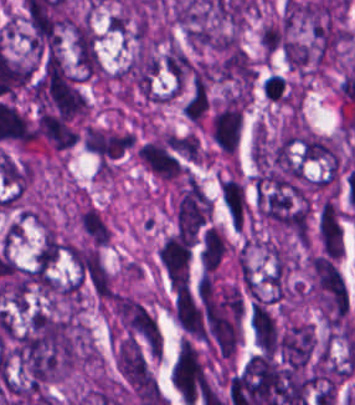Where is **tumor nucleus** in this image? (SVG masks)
<instances>
[{
	"instance_id": "obj_1",
	"label": "tumor nucleus",
	"mask_w": 355,
	"mask_h": 405,
	"mask_svg": "<svg viewBox=\"0 0 355 405\" xmlns=\"http://www.w3.org/2000/svg\"><path fill=\"white\" fill-rule=\"evenodd\" d=\"M309 293L327 318L340 317L348 310L344 277L329 256L311 252L308 256Z\"/></svg>"
},
{
	"instance_id": "obj_2",
	"label": "tumor nucleus",
	"mask_w": 355,
	"mask_h": 405,
	"mask_svg": "<svg viewBox=\"0 0 355 405\" xmlns=\"http://www.w3.org/2000/svg\"><path fill=\"white\" fill-rule=\"evenodd\" d=\"M244 112L243 91H227L212 104L209 135L215 148L233 154L241 140Z\"/></svg>"
},
{
	"instance_id": "obj_3",
	"label": "tumor nucleus",
	"mask_w": 355,
	"mask_h": 405,
	"mask_svg": "<svg viewBox=\"0 0 355 405\" xmlns=\"http://www.w3.org/2000/svg\"><path fill=\"white\" fill-rule=\"evenodd\" d=\"M69 262L78 280L94 295L113 292L112 280L99 247L87 242H73L67 247Z\"/></svg>"
},
{
	"instance_id": "obj_4",
	"label": "tumor nucleus",
	"mask_w": 355,
	"mask_h": 405,
	"mask_svg": "<svg viewBox=\"0 0 355 405\" xmlns=\"http://www.w3.org/2000/svg\"><path fill=\"white\" fill-rule=\"evenodd\" d=\"M315 239L319 252L338 258L343 243V227L341 210L333 195L325 194L317 204Z\"/></svg>"
},
{
	"instance_id": "obj_5",
	"label": "tumor nucleus",
	"mask_w": 355,
	"mask_h": 405,
	"mask_svg": "<svg viewBox=\"0 0 355 405\" xmlns=\"http://www.w3.org/2000/svg\"><path fill=\"white\" fill-rule=\"evenodd\" d=\"M156 255L173 285L186 276L190 249L179 232L165 236Z\"/></svg>"
},
{
	"instance_id": "obj_6",
	"label": "tumor nucleus",
	"mask_w": 355,
	"mask_h": 405,
	"mask_svg": "<svg viewBox=\"0 0 355 405\" xmlns=\"http://www.w3.org/2000/svg\"><path fill=\"white\" fill-rule=\"evenodd\" d=\"M78 226L88 242L103 246L110 238L108 222L92 204L83 203L77 213Z\"/></svg>"
},
{
	"instance_id": "obj_7",
	"label": "tumor nucleus",
	"mask_w": 355,
	"mask_h": 405,
	"mask_svg": "<svg viewBox=\"0 0 355 405\" xmlns=\"http://www.w3.org/2000/svg\"><path fill=\"white\" fill-rule=\"evenodd\" d=\"M226 251V243L216 226H209L201 237L200 262L204 272H212Z\"/></svg>"
},
{
	"instance_id": "obj_8",
	"label": "tumor nucleus",
	"mask_w": 355,
	"mask_h": 405,
	"mask_svg": "<svg viewBox=\"0 0 355 405\" xmlns=\"http://www.w3.org/2000/svg\"><path fill=\"white\" fill-rule=\"evenodd\" d=\"M226 210L242 227L247 215L248 200L246 191L237 176H224Z\"/></svg>"
}]
</instances>
